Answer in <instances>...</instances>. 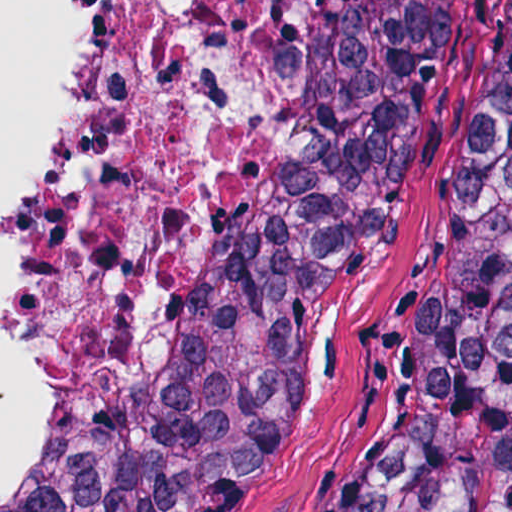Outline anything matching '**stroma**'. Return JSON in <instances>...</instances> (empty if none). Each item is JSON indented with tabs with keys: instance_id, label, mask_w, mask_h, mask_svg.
<instances>
[{
	"instance_id": "obj_1",
	"label": "stroma",
	"mask_w": 512,
	"mask_h": 512,
	"mask_svg": "<svg viewBox=\"0 0 512 512\" xmlns=\"http://www.w3.org/2000/svg\"><path fill=\"white\" fill-rule=\"evenodd\" d=\"M512 0H433L310 359L222 512H358L426 369L430 315L495 106ZM19 485L0 496L6 512Z\"/></svg>"
}]
</instances>
